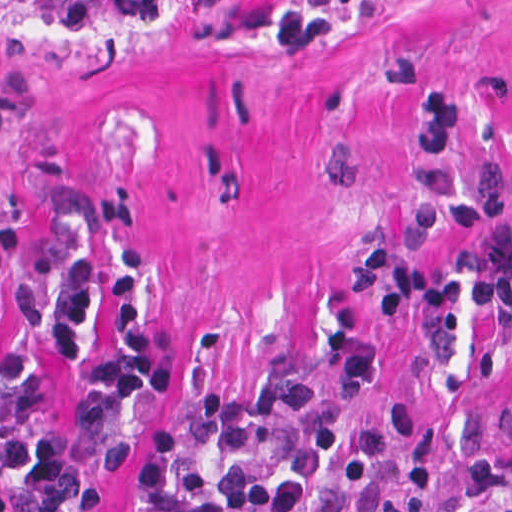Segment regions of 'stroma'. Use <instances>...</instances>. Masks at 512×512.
I'll list each match as a JSON object with an SVG mask.
<instances>
[{"mask_svg":"<svg viewBox=\"0 0 512 512\" xmlns=\"http://www.w3.org/2000/svg\"><path fill=\"white\" fill-rule=\"evenodd\" d=\"M417 76L462 96L453 160L419 158ZM428 165L458 190L512 172V0H361L314 46L215 0H0V237L91 270L78 357L55 350L47 295L28 448L74 410L93 363L120 355L116 280L137 249L135 309L175 378L131 415L96 512H131L154 432L190 399L283 378L432 417L435 511L502 512L512 315L378 322L340 287L381 242L428 263L462 249L459 231L417 223ZM26 279L0 255L11 345L28 337L14 304ZM13 471L0 499L24 512Z\"/></svg>","mask_w":512,"mask_h":512,"instance_id":"1","label":"stroma"}]
</instances>
